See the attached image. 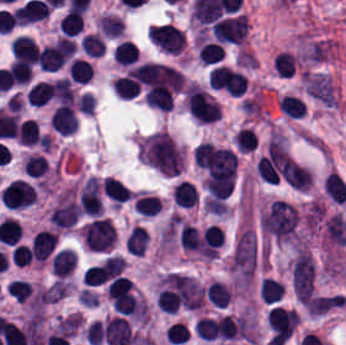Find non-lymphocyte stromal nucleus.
I'll return each instance as SVG.
<instances>
[{
  "mask_svg": "<svg viewBox=\"0 0 346 345\" xmlns=\"http://www.w3.org/2000/svg\"><path fill=\"white\" fill-rule=\"evenodd\" d=\"M138 157L161 174H179L186 161L183 148L166 130L156 131L140 139Z\"/></svg>",
  "mask_w": 346,
  "mask_h": 345,
  "instance_id": "obj_1",
  "label": "non-lymphocyte stromal nucleus"
},
{
  "mask_svg": "<svg viewBox=\"0 0 346 345\" xmlns=\"http://www.w3.org/2000/svg\"><path fill=\"white\" fill-rule=\"evenodd\" d=\"M257 266V241L247 226L238 236L230 258L235 288H247Z\"/></svg>",
  "mask_w": 346,
  "mask_h": 345,
  "instance_id": "obj_2",
  "label": "non-lymphocyte stromal nucleus"
},
{
  "mask_svg": "<svg viewBox=\"0 0 346 345\" xmlns=\"http://www.w3.org/2000/svg\"><path fill=\"white\" fill-rule=\"evenodd\" d=\"M303 82L309 95L329 107L338 106L339 102L330 75L305 71Z\"/></svg>",
  "mask_w": 346,
  "mask_h": 345,
  "instance_id": "obj_3",
  "label": "non-lymphocyte stromal nucleus"
}]
</instances>
